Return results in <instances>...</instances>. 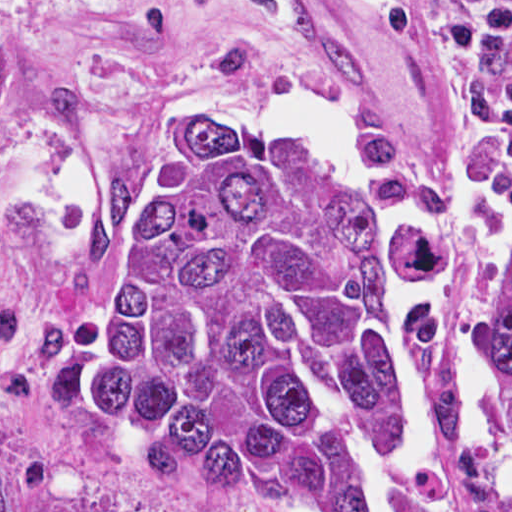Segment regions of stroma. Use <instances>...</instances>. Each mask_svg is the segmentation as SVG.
<instances>
[{"label": "stroma", "mask_w": 512, "mask_h": 512, "mask_svg": "<svg viewBox=\"0 0 512 512\" xmlns=\"http://www.w3.org/2000/svg\"><path fill=\"white\" fill-rule=\"evenodd\" d=\"M296 93L334 100L361 161L406 191L465 195L512 170V132L469 127L427 42L364 0H0V473L38 511L325 512L130 463L68 374L76 220L114 129L209 101L279 130V98Z\"/></svg>", "instance_id": "35a3bbf8"}]
</instances>
